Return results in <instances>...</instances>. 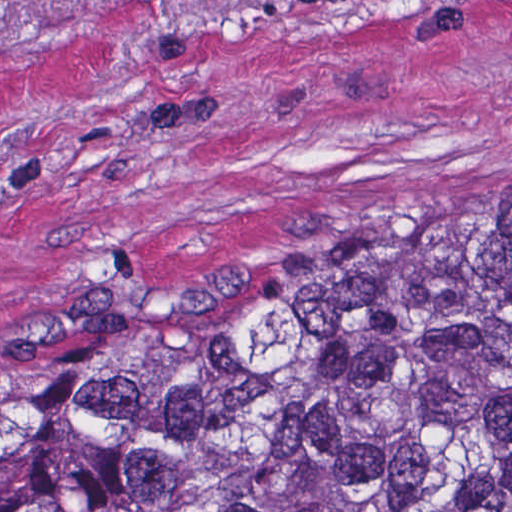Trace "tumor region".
<instances>
[{"label": "tumor region", "instance_id": "obj_1", "mask_svg": "<svg viewBox=\"0 0 512 512\" xmlns=\"http://www.w3.org/2000/svg\"><path fill=\"white\" fill-rule=\"evenodd\" d=\"M0 512H512V191L167 295L84 274L0 392Z\"/></svg>", "mask_w": 512, "mask_h": 512}]
</instances>
